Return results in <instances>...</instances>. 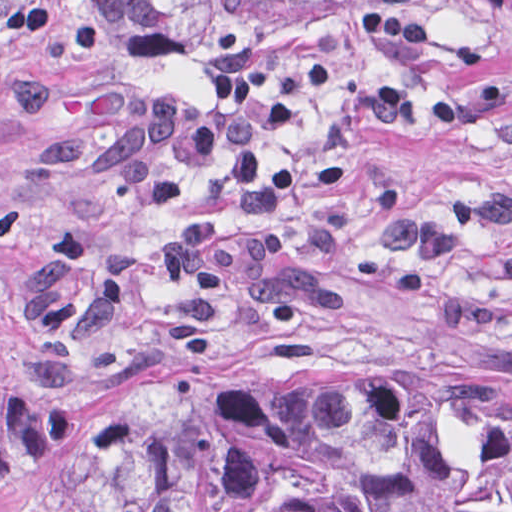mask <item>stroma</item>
Wrapping results in <instances>:
<instances>
[{
	"label": "stroma",
	"mask_w": 512,
	"mask_h": 512,
	"mask_svg": "<svg viewBox=\"0 0 512 512\" xmlns=\"http://www.w3.org/2000/svg\"><path fill=\"white\" fill-rule=\"evenodd\" d=\"M324 62L301 122L258 135L296 171L277 218L230 206L224 153L156 154L176 209L121 197L158 93ZM230 371L512 384V8L150 59L97 0H0V512H60L95 408Z\"/></svg>",
	"instance_id": "1"
}]
</instances>
